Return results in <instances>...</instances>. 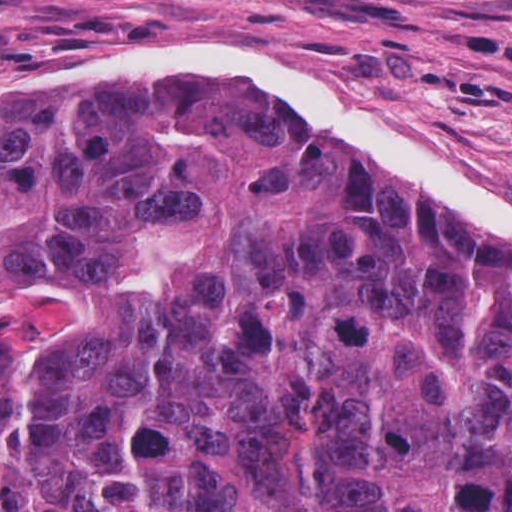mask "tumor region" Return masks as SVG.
Returning <instances> with one entry per match:
<instances>
[{"instance_id": "tumor-region-1", "label": "tumor region", "mask_w": 512, "mask_h": 512, "mask_svg": "<svg viewBox=\"0 0 512 512\" xmlns=\"http://www.w3.org/2000/svg\"><path fill=\"white\" fill-rule=\"evenodd\" d=\"M0 512H512V244L249 82L0 92Z\"/></svg>"}]
</instances>
